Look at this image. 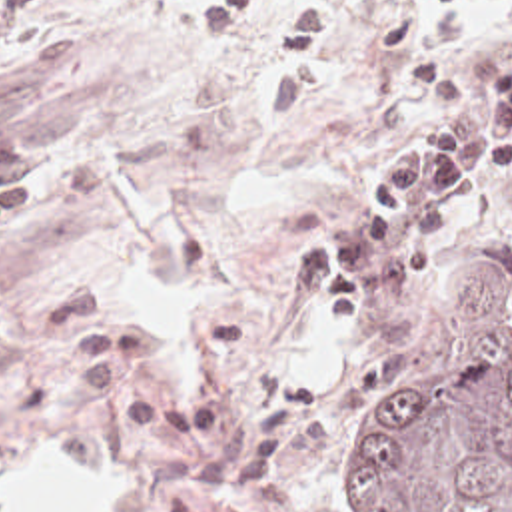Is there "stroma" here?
<instances>
[{"mask_svg":"<svg viewBox=\"0 0 512 512\" xmlns=\"http://www.w3.org/2000/svg\"><path fill=\"white\" fill-rule=\"evenodd\" d=\"M512 27V0H302L270 33L256 9L208 43L181 0H47L31 51L0 67V135L45 160V192L0 242V476L33 446L137 472V512H356L348 444L498 332L456 338L454 292L512 282V170L460 216L410 292L332 312L300 254L384 154L430 123L414 61L464 75ZM159 188L155 270L206 286L192 400L127 296L133 222L119 196ZM336 322V388L310 384L294 324Z\"/></svg>","mask_w":512,"mask_h":512,"instance_id":"1","label":"stroma"}]
</instances>
